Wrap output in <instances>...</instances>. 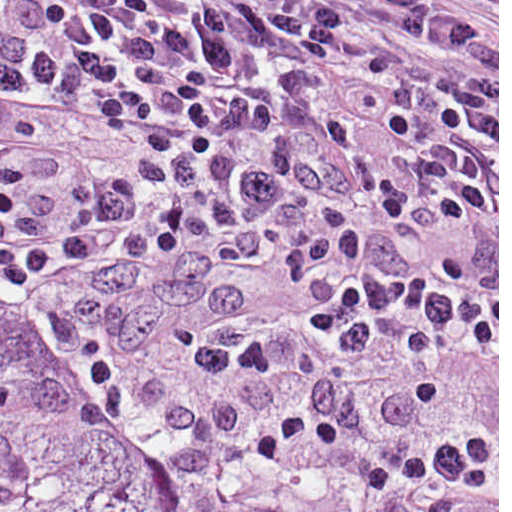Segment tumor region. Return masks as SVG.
<instances>
[{
  "label": "tumor region",
  "instance_id": "obj_1",
  "mask_svg": "<svg viewBox=\"0 0 512 512\" xmlns=\"http://www.w3.org/2000/svg\"><path fill=\"white\" fill-rule=\"evenodd\" d=\"M0 512H300L104 430L0 270Z\"/></svg>",
  "mask_w": 512,
  "mask_h": 512
}]
</instances>
